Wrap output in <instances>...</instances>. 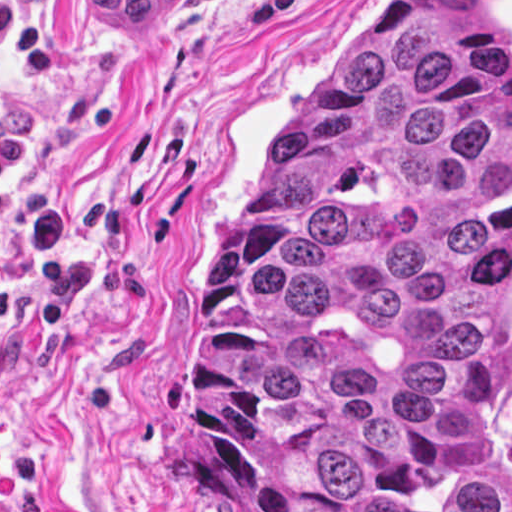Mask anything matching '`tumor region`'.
Masks as SVG:
<instances>
[{
	"instance_id": "e687c5a6",
	"label": "tumor region",
	"mask_w": 512,
	"mask_h": 512,
	"mask_svg": "<svg viewBox=\"0 0 512 512\" xmlns=\"http://www.w3.org/2000/svg\"><path fill=\"white\" fill-rule=\"evenodd\" d=\"M223 512H512V63L487 0H382L275 129L185 317Z\"/></svg>"
}]
</instances>
